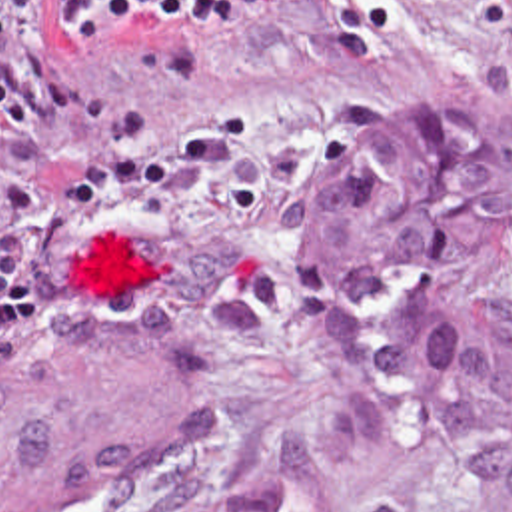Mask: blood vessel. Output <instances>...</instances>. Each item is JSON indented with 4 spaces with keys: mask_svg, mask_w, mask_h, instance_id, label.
Here are the masks:
<instances>
[{
    "mask_svg": "<svg viewBox=\"0 0 512 512\" xmlns=\"http://www.w3.org/2000/svg\"><path fill=\"white\" fill-rule=\"evenodd\" d=\"M0 350V512H147L201 457L211 368L185 338Z\"/></svg>",
    "mask_w": 512,
    "mask_h": 512,
    "instance_id": "8fb6f2fc",
    "label": "blood vessel"
}]
</instances>
